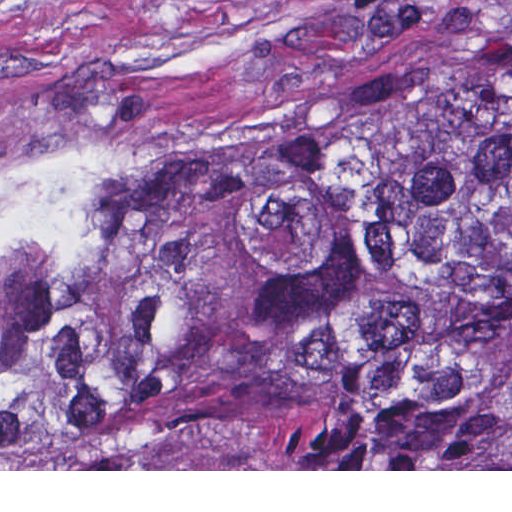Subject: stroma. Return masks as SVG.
I'll list each match as a JSON object with an SVG mask.
<instances>
[{"label": "stroma", "instance_id": "35a3bbf8", "mask_svg": "<svg viewBox=\"0 0 512 512\" xmlns=\"http://www.w3.org/2000/svg\"><path fill=\"white\" fill-rule=\"evenodd\" d=\"M470 21L512 24V0H0V471H512L1 469V213L14 199L168 161L270 85Z\"/></svg>", "mask_w": 512, "mask_h": 512}]
</instances>
